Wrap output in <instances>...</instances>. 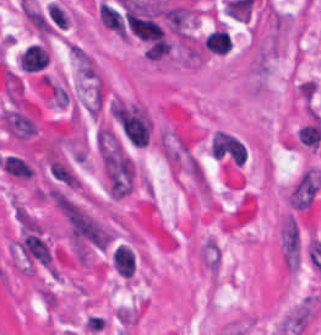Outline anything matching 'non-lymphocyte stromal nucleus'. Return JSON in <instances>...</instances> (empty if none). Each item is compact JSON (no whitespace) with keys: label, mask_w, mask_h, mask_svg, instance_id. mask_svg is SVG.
<instances>
[{"label":"non-lymphocyte stromal nucleus","mask_w":321,"mask_h":335,"mask_svg":"<svg viewBox=\"0 0 321 335\" xmlns=\"http://www.w3.org/2000/svg\"><path fill=\"white\" fill-rule=\"evenodd\" d=\"M96 145L108 195L118 198L132 190L137 166L117 137L99 133Z\"/></svg>","instance_id":"non-lymphocyte-stromal-nucleus-1"},{"label":"non-lymphocyte stromal nucleus","mask_w":321,"mask_h":335,"mask_svg":"<svg viewBox=\"0 0 321 335\" xmlns=\"http://www.w3.org/2000/svg\"><path fill=\"white\" fill-rule=\"evenodd\" d=\"M279 252L287 271H295L305 253V243L300 221L291 212L287 214L279 227Z\"/></svg>","instance_id":"non-lymphocyte-stromal-nucleus-2"},{"label":"non-lymphocyte stromal nucleus","mask_w":321,"mask_h":335,"mask_svg":"<svg viewBox=\"0 0 321 335\" xmlns=\"http://www.w3.org/2000/svg\"><path fill=\"white\" fill-rule=\"evenodd\" d=\"M321 191V170L308 166L287 193L288 208L294 213L309 209Z\"/></svg>","instance_id":"non-lymphocyte-stromal-nucleus-3"}]
</instances>
